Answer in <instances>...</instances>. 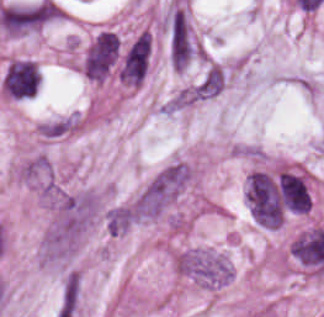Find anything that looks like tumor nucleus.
<instances>
[{
	"label": "tumor nucleus",
	"mask_w": 324,
	"mask_h": 317,
	"mask_svg": "<svg viewBox=\"0 0 324 317\" xmlns=\"http://www.w3.org/2000/svg\"><path fill=\"white\" fill-rule=\"evenodd\" d=\"M276 192L288 213H306L311 205L310 190L304 176L291 169L279 173Z\"/></svg>",
	"instance_id": "tumor-nucleus-2"
},
{
	"label": "tumor nucleus",
	"mask_w": 324,
	"mask_h": 317,
	"mask_svg": "<svg viewBox=\"0 0 324 317\" xmlns=\"http://www.w3.org/2000/svg\"><path fill=\"white\" fill-rule=\"evenodd\" d=\"M72 123L69 117H62L40 124L41 133L49 137H61L71 129Z\"/></svg>",
	"instance_id": "tumor-nucleus-4"
},
{
	"label": "tumor nucleus",
	"mask_w": 324,
	"mask_h": 317,
	"mask_svg": "<svg viewBox=\"0 0 324 317\" xmlns=\"http://www.w3.org/2000/svg\"><path fill=\"white\" fill-rule=\"evenodd\" d=\"M226 82L224 66L213 63L202 75L194 87V95L198 98H208L222 90Z\"/></svg>",
	"instance_id": "tumor-nucleus-3"
},
{
	"label": "tumor nucleus",
	"mask_w": 324,
	"mask_h": 317,
	"mask_svg": "<svg viewBox=\"0 0 324 317\" xmlns=\"http://www.w3.org/2000/svg\"><path fill=\"white\" fill-rule=\"evenodd\" d=\"M40 83V68L30 59L18 58L6 66L1 86L14 98H25L37 91Z\"/></svg>",
	"instance_id": "tumor-nucleus-1"
}]
</instances>
